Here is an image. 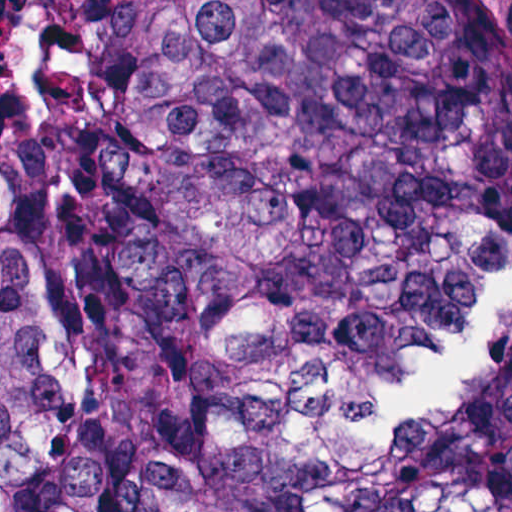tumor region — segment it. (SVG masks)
<instances>
[{"label":"tumor region","mask_w":512,"mask_h":512,"mask_svg":"<svg viewBox=\"0 0 512 512\" xmlns=\"http://www.w3.org/2000/svg\"><path fill=\"white\" fill-rule=\"evenodd\" d=\"M0 512H512V0H24Z\"/></svg>","instance_id":"1"}]
</instances>
